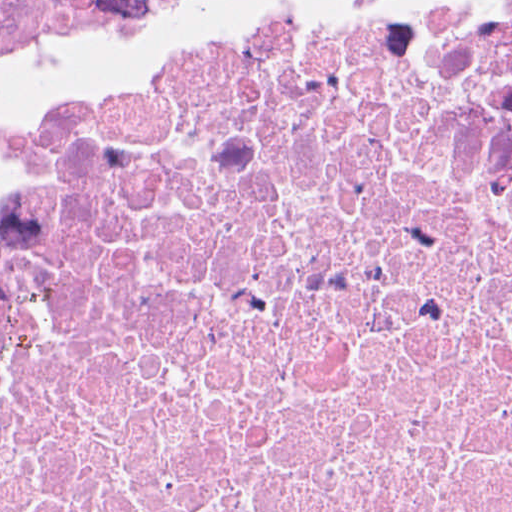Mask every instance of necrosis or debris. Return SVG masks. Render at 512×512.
Instances as JSON below:
<instances>
[{"label": "necrosis or debris", "mask_w": 512, "mask_h": 512, "mask_svg": "<svg viewBox=\"0 0 512 512\" xmlns=\"http://www.w3.org/2000/svg\"><path fill=\"white\" fill-rule=\"evenodd\" d=\"M0 512H512V0L279 9L43 125Z\"/></svg>", "instance_id": "4bbe7bcc"}]
</instances>
